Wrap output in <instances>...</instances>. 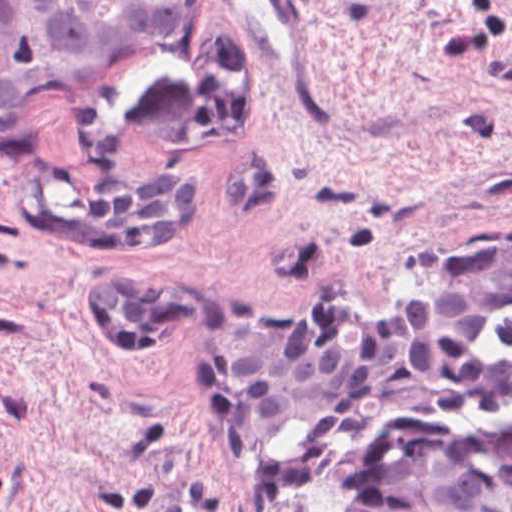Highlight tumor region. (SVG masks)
<instances>
[{
	"mask_svg": "<svg viewBox=\"0 0 512 512\" xmlns=\"http://www.w3.org/2000/svg\"><path fill=\"white\" fill-rule=\"evenodd\" d=\"M96 187L89 209L44 216L40 233L76 250H164L203 223L196 170ZM332 299L263 305L235 321L227 405L252 483L308 476L380 417L508 394V376L480 353L493 322L512 311V240L443 256L384 310L350 311ZM90 307L108 339L159 341L216 316L219 299L182 279L124 274L93 279Z\"/></svg>",
	"mask_w": 512,
	"mask_h": 512,
	"instance_id": "e687c5a6",
	"label": "tumor region"
}]
</instances>
